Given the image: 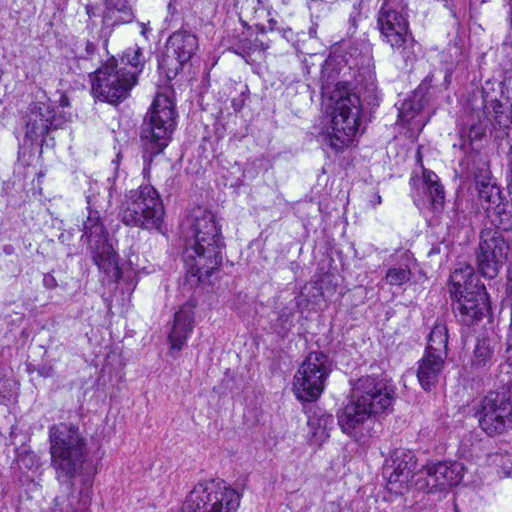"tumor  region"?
<instances>
[{
    "instance_id": "obj_1",
    "label": "tumor region",
    "mask_w": 512,
    "mask_h": 512,
    "mask_svg": "<svg viewBox=\"0 0 512 512\" xmlns=\"http://www.w3.org/2000/svg\"><path fill=\"white\" fill-rule=\"evenodd\" d=\"M0 512H512V0H0Z\"/></svg>"
}]
</instances>
